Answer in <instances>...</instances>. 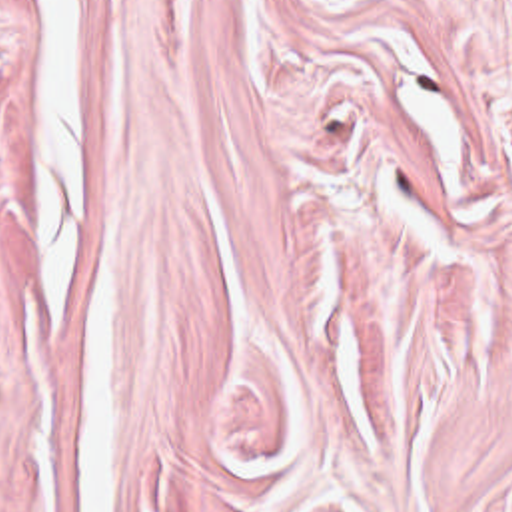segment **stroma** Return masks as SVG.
I'll return each mask as SVG.
<instances>
[{"label":"stroma","mask_w":512,"mask_h":512,"mask_svg":"<svg viewBox=\"0 0 512 512\" xmlns=\"http://www.w3.org/2000/svg\"><path fill=\"white\" fill-rule=\"evenodd\" d=\"M75 3L103 512H512V0ZM0 512H83L41 0H0Z\"/></svg>","instance_id":"obj_1"}]
</instances>
